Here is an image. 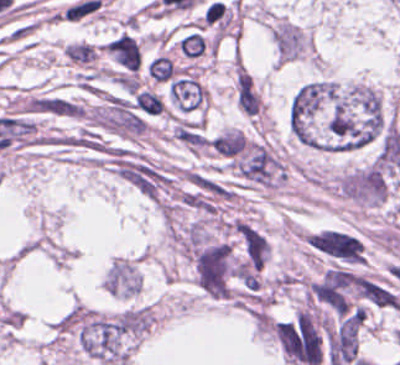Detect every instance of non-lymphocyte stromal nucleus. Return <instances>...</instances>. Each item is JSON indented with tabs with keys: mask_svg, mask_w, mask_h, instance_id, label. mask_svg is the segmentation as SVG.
I'll list each match as a JSON object with an SVG mask.
<instances>
[{
	"mask_svg": "<svg viewBox=\"0 0 400 365\" xmlns=\"http://www.w3.org/2000/svg\"><path fill=\"white\" fill-rule=\"evenodd\" d=\"M114 67L128 72H139L143 66V48L137 35L121 30L103 45Z\"/></svg>",
	"mask_w": 400,
	"mask_h": 365,
	"instance_id": "non-lymphocyte-stromal-nucleus-1",
	"label": "non-lymphocyte stromal nucleus"
},
{
	"mask_svg": "<svg viewBox=\"0 0 400 365\" xmlns=\"http://www.w3.org/2000/svg\"><path fill=\"white\" fill-rule=\"evenodd\" d=\"M234 91L237 107L250 116H255L262 101L261 95L248 71L242 65L234 67Z\"/></svg>",
	"mask_w": 400,
	"mask_h": 365,
	"instance_id": "non-lymphocyte-stromal-nucleus-2",
	"label": "non-lymphocyte stromal nucleus"
},
{
	"mask_svg": "<svg viewBox=\"0 0 400 365\" xmlns=\"http://www.w3.org/2000/svg\"><path fill=\"white\" fill-rule=\"evenodd\" d=\"M168 94L181 109H189L207 97V88L194 76H180L170 81Z\"/></svg>",
	"mask_w": 400,
	"mask_h": 365,
	"instance_id": "non-lymphocyte-stromal-nucleus-3",
	"label": "non-lymphocyte stromal nucleus"
},
{
	"mask_svg": "<svg viewBox=\"0 0 400 365\" xmlns=\"http://www.w3.org/2000/svg\"><path fill=\"white\" fill-rule=\"evenodd\" d=\"M175 46L179 55L188 60L206 56L215 48L210 36L204 30L195 28L178 36Z\"/></svg>",
	"mask_w": 400,
	"mask_h": 365,
	"instance_id": "non-lymphocyte-stromal-nucleus-4",
	"label": "non-lymphocyte stromal nucleus"
},
{
	"mask_svg": "<svg viewBox=\"0 0 400 365\" xmlns=\"http://www.w3.org/2000/svg\"><path fill=\"white\" fill-rule=\"evenodd\" d=\"M179 71L169 55H155L145 61V77L154 83H167Z\"/></svg>",
	"mask_w": 400,
	"mask_h": 365,
	"instance_id": "non-lymphocyte-stromal-nucleus-5",
	"label": "non-lymphocyte stromal nucleus"
},
{
	"mask_svg": "<svg viewBox=\"0 0 400 365\" xmlns=\"http://www.w3.org/2000/svg\"><path fill=\"white\" fill-rule=\"evenodd\" d=\"M64 58L79 66H92L98 60L97 44L86 40H72L64 46Z\"/></svg>",
	"mask_w": 400,
	"mask_h": 365,
	"instance_id": "non-lymphocyte-stromal-nucleus-6",
	"label": "non-lymphocyte stromal nucleus"
},
{
	"mask_svg": "<svg viewBox=\"0 0 400 365\" xmlns=\"http://www.w3.org/2000/svg\"><path fill=\"white\" fill-rule=\"evenodd\" d=\"M133 105L148 115L163 112V101L159 94L144 88L136 92Z\"/></svg>",
	"mask_w": 400,
	"mask_h": 365,
	"instance_id": "non-lymphocyte-stromal-nucleus-7",
	"label": "non-lymphocyte stromal nucleus"
}]
</instances>
